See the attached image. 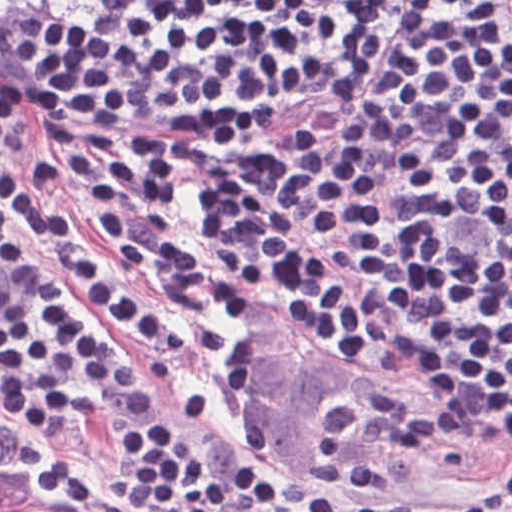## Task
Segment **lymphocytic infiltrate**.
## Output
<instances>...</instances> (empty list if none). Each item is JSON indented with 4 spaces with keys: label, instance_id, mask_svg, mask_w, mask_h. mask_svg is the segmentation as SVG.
<instances>
[{
    "label": "lymphocytic infiltrate",
    "instance_id": "lymphocytic-infiltrate-1",
    "mask_svg": "<svg viewBox=\"0 0 512 512\" xmlns=\"http://www.w3.org/2000/svg\"><path fill=\"white\" fill-rule=\"evenodd\" d=\"M69 0H0V33ZM376 0H102L51 15L31 37L17 111L68 169L15 141L0 81V425L65 439L78 417L119 434V493L145 512H474L495 502L341 490L262 465L237 394V432L262 468L199 460L178 428L207 395L159 410L169 366L114 347L178 350L181 328L110 260L82 247L50 267L11 233L97 240L141 268L189 318L229 289L285 306L316 338L457 410L512 424V0H431L393 63L323 147L283 176L404 297L410 331L317 266L214 212L204 193L185 245L184 172L260 148L264 92L332 59Z\"/></svg>",
    "mask_w": 512,
    "mask_h": 512
}]
</instances>
